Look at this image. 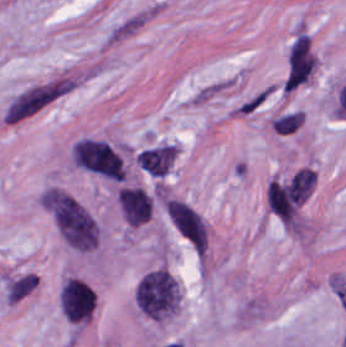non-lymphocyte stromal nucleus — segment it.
<instances>
[{
	"label": "non-lymphocyte stromal nucleus",
	"instance_id": "1",
	"mask_svg": "<svg viewBox=\"0 0 346 347\" xmlns=\"http://www.w3.org/2000/svg\"><path fill=\"white\" fill-rule=\"evenodd\" d=\"M90 70L69 67L12 93L4 103L0 123L19 124L79 89Z\"/></svg>",
	"mask_w": 346,
	"mask_h": 347
},
{
	"label": "non-lymphocyte stromal nucleus",
	"instance_id": "2",
	"mask_svg": "<svg viewBox=\"0 0 346 347\" xmlns=\"http://www.w3.org/2000/svg\"><path fill=\"white\" fill-rule=\"evenodd\" d=\"M316 56L306 33H299L286 55L282 92H290L311 75Z\"/></svg>",
	"mask_w": 346,
	"mask_h": 347
},
{
	"label": "non-lymphocyte stromal nucleus",
	"instance_id": "3",
	"mask_svg": "<svg viewBox=\"0 0 346 347\" xmlns=\"http://www.w3.org/2000/svg\"><path fill=\"white\" fill-rule=\"evenodd\" d=\"M156 8L157 4L153 0L122 14L109 26L105 34L106 43L111 45L131 36L150 20Z\"/></svg>",
	"mask_w": 346,
	"mask_h": 347
},
{
	"label": "non-lymphocyte stromal nucleus",
	"instance_id": "4",
	"mask_svg": "<svg viewBox=\"0 0 346 347\" xmlns=\"http://www.w3.org/2000/svg\"><path fill=\"white\" fill-rule=\"evenodd\" d=\"M234 83L233 76H219L203 83L191 94L188 101L192 106H203L234 86Z\"/></svg>",
	"mask_w": 346,
	"mask_h": 347
},
{
	"label": "non-lymphocyte stromal nucleus",
	"instance_id": "5",
	"mask_svg": "<svg viewBox=\"0 0 346 347\" xmlns=\"http://www.w3.org/2000/svg\"><path fill=\"white\" fill-rule=\"evenodd\" d=\"M275 92V83H268L259 88L234 106L235 116L250 117L259 112Z\"/></svg>",
	"mask_w": 346,
	"mask_h": 347
}]
</instances>
